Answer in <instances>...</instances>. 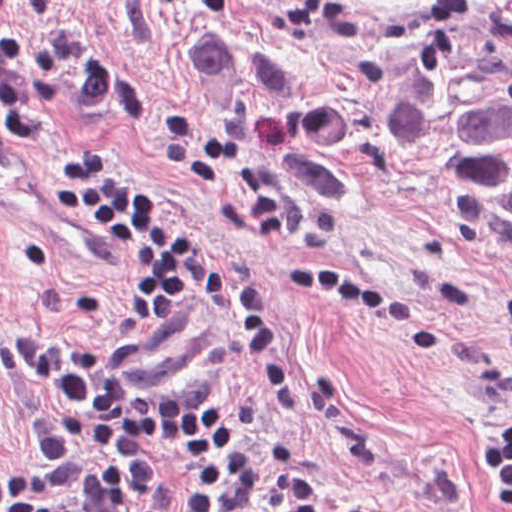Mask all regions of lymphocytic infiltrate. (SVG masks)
Segmentation results:
<instances>
[{"instance_id": "obj_1", "label": "lymphocytic infiltrate", "mask_w": 512, "mask_h": 512, "mask_svg": "<svg viewBox=\"0 0 512 512\" xmlns=\"http://www.w3.org/2000/svg\"><path fill=\"white\" fill-rule=\"evenodd\" d=\"M13 0H0L7 8ZM106 74L75 64L48 45L0 37V122L11 139L48 158L50 209L93 225L103 239L129 248L147 266L132 308L134 323L159 329L183 309L190 288L244 322V343L277 412L291 405V374L275 311L255 278L203 257L180 215L124 170L116 152L65 151L54 126L27 97L62 90L104 100ZM158 150L224 181L258 231L288 232L295 206L275 207L271 180L253 177L246 153L206 134L182 107L165 110ZM322 287L359 312H370L410 337L415 353H433L439 330L394 287L314 264L278 271ZM492 323L512 366V287L495 299ZM20 366L52 408L32 423L33 468L17 481L0 477V512H125L127 503L168 469L173 448L228 449L244 424L201 382L163 393L136 389L99 342L43 334L12 335ZM302 448L266 443L219 461L181 481L149 512H379L361 496L306 474ZM483 486L497 512H512V415L494 422L482 455Z\"/></svg>"}]
</instances>
